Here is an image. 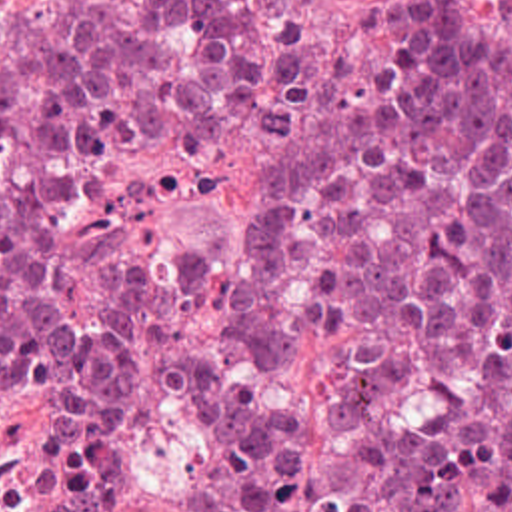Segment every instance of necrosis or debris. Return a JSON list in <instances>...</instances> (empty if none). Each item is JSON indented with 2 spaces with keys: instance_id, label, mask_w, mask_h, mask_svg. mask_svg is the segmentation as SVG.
I'll return each instance as SVG.
<instances>
[{
  "instance_id": "necrosis-or-debris-1",
  "label": "necrosis or debris",
  "mask_w": 512,
  "mask_h": 512,
  "mask_svg": "<svg viewBox=\"0 0 512 512\" xmlns=\"http://www.w3.org/2000/svg\"><path fill=\"white\" fill-rule=\"evenodd\" d=\"M0 512H69L67 401L19 347H0Z\"/></svg>"
}]
</instances>
